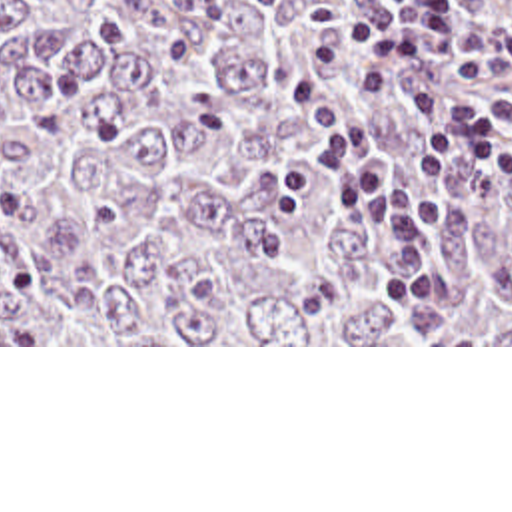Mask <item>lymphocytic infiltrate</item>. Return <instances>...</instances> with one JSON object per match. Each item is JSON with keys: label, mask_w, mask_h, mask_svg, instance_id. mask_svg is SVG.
<instances>
[{"label": "lymphocytic infiltrate", "mask_w": 512, "mask_h": 512, "mask_svg": "<svg viewBox=\"0 0 512 512\" xmlns=\"http://www.w3.org/2000/svg\"><path fill=\"white\" fill-rule=\"evenodd\" d=\"M168 0H58L94 44L128 38L124 6L150 10ZM350 36L362 54L382 57L356 77V91L380 97L390 73L408 59L430 57L452 81L502 85L512 81V12L494 28H470L450 0H394L372 10L312 6L300 24V52L322 73L340 69L344 56L330 32ZM292 101L320 145L302 157L320 183L350 203V215L386 235L412 271H430L442 217V179L458 157L492 171H512V97H448L418 91L422 137L408 167L376 149L364 129L314 81L294 79Z\"/></svg>", "instance_id": "obj_1"}]
</instances>
